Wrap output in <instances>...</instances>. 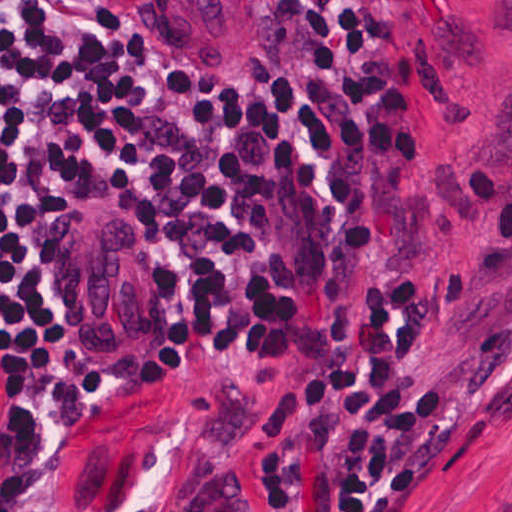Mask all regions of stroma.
<instances>
[{
    "instance_id": "35a3bbf8",
    "label": "stroma",
    "mask_w": 512,
    "mask_h": 512,
    "mask_svg": "<svg viewBox=\"0 0 512 512\" xmlns=\"http://www.w3.org/2000/svg\"><path fill=\"white\" fill-rule=\"evenodd\" d=\"M251 11V57L182 60L129 35L113 19V87L74 142L41 204L30 275L35 317L87 352L106 383V429L73 454L17 450L11 377L0 355V498L33 512H174L201 472L238 474V439L260 387H224L193 369L190 273L184 260L115 201L105 175L110 117L146 73H192L219 87L264 89L269 0ZM385 36L429 70L426 158L400 175L403 275L416 289L461 270L475 251L469 195L474 168L512 175V0H393ZM97 204L149 251L165 367H124L95 341L59 293L57 228ZM415 369L458 394L460 431L395 512H512V270L474 296L441 330Z\"/></svg>"
}]
</instances>
